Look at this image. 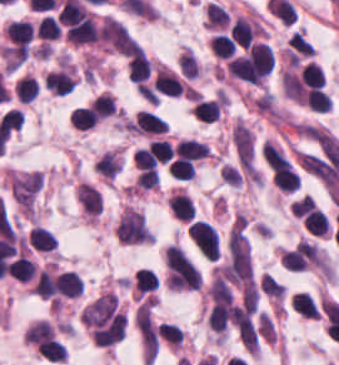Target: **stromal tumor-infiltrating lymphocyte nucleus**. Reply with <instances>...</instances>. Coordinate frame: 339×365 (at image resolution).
Masks as SVG:
<instances>
[{
    "mask_svg": "<svg viewBox=\"0 0 339 365\" xmlns=\"http://www.w3.org/2000/svg\"><path fill=\"white\" fill-rule=\"evenodd\" d=\"M188 236L207 259H218V232L206 221L193 220L188 225Z\"/></svg>",
    "mask_w": 339,
    "mask_h": 365,
    "instance_id": "1",
    "label": "stromal tumor-infiltrating lymphocyte nucleus"
},
{
    "mask_svg": "<svg viewBox=\"0 0 339 365\" xmlns=\"http://www.w3.org/2000/svg\"><path fill=\"white\" fill-rule=\"evenodd\" d=\"M167 124L157 114L147 109H139L129 123V130L146 134H158L164 132Z\"/></svg>",
    "mask_w": 339,
    "mask_h": 365,
    "instance_id": "2",
    "label": "stromal tumor-infiltrating lymphocyte nucleus"
},
{
    "mask_svg": "<svg viewBox=\"0 0 339 365\" xmlns=\"http://www.w3.org/2000/svg\"><path fill=\"white\" fill-rule=\"evenodd\" d=\"M153 86L158 93L177 97L183 88L177 74L162 65L157 68Z\"/></svg>",
    "mask_w": 339,
    "mask_h": 365,
    "instance_id": "3",
    "label": "stromal tumor-infiltrating lymphocyte nucleus"
},
{
    "mask_svg": "<svg viewBox=\"0 0 339 365\" xmlns=\"http://www.w3.org/2000/svg\"><path fill=\"white\" fill-rule=\"evenodd\" d=\"M230 34L236 44L246 49L258 34V23L237 17L232 23Z\"/></svg>",
    "mask_w": 339,
    "mask_h": 365,
    "instance_id": "4",
    "label": "stromal tumor-infiltrating lymphocyte nucleus"
},
{
    "mask_svg": "<svg viewBox=\"0 0 339 365\" xmlns=\"http://www.w3.org/2000/svg\"><path fill=\"white\" fill-rule=\"evenodd\" d=\"M43 85L45 89L63 97L73 90L75 83L72 75L61 69L48 72L45 75Z\"/></svg>",
    "mask_w": 339,
    "mask_h": 365,
    "instance_id": "5",
    "label": "stromal tumor-infiltrating lymphocyte nucleus"
},
{
    "mask_svg": "<svg viewBox=\"0 0 339 365\" xmlns=\"http://www.w3.org/2000/svg\"><path fill=\"white\" fill-rule=\"evenodd\" d=\"M175 153L178 157L198 160L207 157L209 146L197 138H183L176 144Z\"/></svg>",
    "mask_w": 339,
    "mask_h": 365,
    "instance_id": "6",
    "label": "stromal tumor-infiltrating lymphocyte nucleus"
},
{
    "mask_svg": "<svg viewBox=\"0 0 339 365\" xmlns=\"http://www.w3.org/2000/svg\"><path fill=\"white\" fill-rule=\"evenodd\" d=\"M57 293L64 297H78L83 293V284L77 273L62 272L56 280Z\"/></svg>",
    "mask_w": 339,
    "mask_h": 365,
    "instance_id": "7",
    "label": "stromal tumor-infiltrating lymphocyte nucleus"
},
{
    "mask_svg": "<svg viewBox=\"0 0 339 365\" xmlns=\"http://www.w3.org/2000/svg\"><path fill=\"white\" fill-rule=\"evenodd\" d=\"M128 78L138 83H144L150 75V62L138 49L133 53L127 63Z\"/></svg>",
    "mask_w": 339,
    "mask_h": 365,
    "instance_id": "8",
    "label": "stromal tumor-infiltrating lymphocyte nucleus"
},
{
    "mask_svg": "<svg viewBox=\"0 0 339 365\" xmlns=\"http://www.w3.org/2000/svg\"><path fill=\"white\" fill-rule=\"evenodd\" d=\"M293 311L301 317L320 319V310L311 296L305 292L293 293L291 296Z\"/></svg>",
    "mask_w": 339,
    "mask_h": 365,
    "instance_id": "9",
    "label": "stromal tumor-infiltrating lymphocyte nucleus"
},
{
    "mask_svg": "<svg viewBox=\"0 0 339 365\" xmlns=\"http://www.w3.org/2000/svg\"><path fill=\"white\" fill-rule=\"evenodd\" d=\"M28 239L32 247L40 252H52L58 247V241L45 227L34 226Z\"/></svg>",
    "mask_w": 339,
    "mask_h": 365,
    "instance_id": "10",
    "label": "stromal tumor-infiltrating lymphocyte nucleus"
},
{
    "mask_svg": "<svg viewBox=\"0 0 339 365\" xmlns=\"http://www.w3.org/2000/svg\"><path fill=\"white\" fill-rule=\"evenodd\" d=\"M291 60H300L315 54V49L303 33L294 31L287 43Z\"/></svg>",
    "mask_w": 339,
    "mask_h": 365,
    "instance_id": "11",
    "label": "stromal tumor-infiltrating lymphocyte nucleus"
},
{
    "mask_svg": "<svg viewBox=\"0 0 339 365\" xmlns=\"http://www.w3.org/2000/svg\"><path fill=\"white\" fill-rule=\"evenodd\" d=\"M173 217L182 222H191L194 214L193 201L183 192H176L171 198Z\"/></svg>",
    "mask_w": 339,
    "mask_h": 365,
    "instance_id": "12",
    "label": "stromal tumor-infiltrating lymphocyte nucleus"
},
{
    "mask_svg": "<svg viewBox=\"0 0 339 365\" xmlns=\"http://www.w3.org/2000/svg\"><path fill=\"white\" fill-rule=\"evenodd\" d=\"M221 109V99L200 98L193 109V114L200 120L212 122L219 117Z\"/></svg>",
    "mask_w": 339,
    "mask_h": 365,
    "instance_id": "13",
    "label": "stromal tumor-infiltrating lymphocyte nucleus"
},
{
    "mask_svg": "<svg viewBox=\"0 0 339 365\" xmlns=\"http://www.w3.org/2000/svg\"><path fill=\"white\" fill-rule=\"evenodd\" d=\"M7 36L14 44H28L34 29L28 20H14L5 29Z\"/></svg>",
    "mask_w": 339,
    "mask_h": 365,
    "instance_id": "14",
    "label": "stromal tumor-infiltrating lymphocyte nucleus"
},
{
    "mask_svg": "<svg viewBox=\"0 0 339 365\" xmlns=\"http://www.w3.org/2000/svg\"><path fill=\"white\" fill-rule=\"evenodd\" d=\"M210 46L217 58H231L236 53V45L227 34H213Z\"/></svg>",
    "mask_w": 339,
    "mask_h": 365,
    "instance_id": "15",
    "label": "stromal tumor-infiltrating lymphocyte nucleus"
},
{
    "mask_svg": "<svg viewBox=\"0 0 339 365\" xmlns=\"http://www.w3.org/2000/svg\"><path fill=\"white\" fill-rule=\"evenodd\" d=\"M136 291L139 295H144L158 288L157 275L148 267H141L134 273Z\"/></svg>",
    "mask_w": 339,
    "mask_h": 365,
    "instance_id": "16",
    "label": "stromal tumor-infiltrating lymphocyte nucleus"
},
{
    "mask_svg": "<svg viewBox=\"0 0 339 365\" xmlns=\"http://www.w3.org/2000/svg\"><path fill=\"white\" fill-rule=\"evenodd\" d=\"M35 34L38 38L55 39L62 34V27L50 15H43L35 25Z\"/></svg>",
    "mask_w": 339,
    "mask_h": 365,
    "instance_id": "17",
    "label": "stromal tumor-infiltrating lymphocyte nucleus"
},
{
    "mask_svg": "<svg viewBox=\"0 0 339 365\" xmlns=\"http://www.w3.org/2000/svg\"><path fill=\"white\" fill-rule=\"evenodd\" d=\"M38 80L25 75L15 83V94L22 103H30L36 98Z\"/></svg>",
    "mask_w": 339,
    "mask_h": 365,
    "instance_id": "18",
    "label": "stromal tumor-infiltrating lymphocyte nucleus"
},
{
    "mask_svg": "<svg viewBox=\"0 0 339 365\" xmlns=\"http://www.w3.org/2000/svg\"><path fill=\"white\" fill-rule=\"evenodd\" d=\"M167 168L169 175L178 179H192L196 172L192 159L184 157L172 159Z\"/></svg>",
    "mask_w": 339,
    "mask_h": 365,
    "instance_id": "19",
    "label": "stromal tumor-infiltrating lymphocyte nucleus"
},
{
    "mask_svg": "<svg viewBox=\"0 0 339 365\" xmlns=\"http://www.w3.org/2000/svg\"><path fill=\"white\" fill-rule=\"evenodd\" d=\"M229 14L214 3L206 5V25L211 29H221L227 26Z\"/></svg>",
    "mask_w": 339,
    "mask_h": 365,
    "instance_id": "20",
    "label": "stromal tumor-infiltrating lymphocyte nucleus"
},
{
    "mask_svg": "<svg viewBox=\"0 0 339 365\" xmlns=\"http://www.w3.org/2000/svg\"><path fill=\"white\" fill-rule=\"evenodd\" d=\"M69 120L79 129H90L98 122L89 107L78 106L70 114Z\"/></svg>",
    "mask_w": 339,
    "mask_h": 365,
    "instance_id": "21",
    "label": "stromal tumor-infiltrating lymphocyte nucleus"
},
{
    "mask_svg": "<svg viewBox=\"0 0 339 365\" xmlns=\"http://www.w3.org/2000/svg\"><path fill=\"white\" fill-rule=\"evenodd\" d=\"M35 265L29 257L18 255L12 260V276L21 281L33 278Z\"/></svg>",
    "mask_w": 339,
    "mask_h": 365,
    "instance_id": "22",
    "label": "stromal tumor-infiltrating lymphocyte nucleus"
},
{
    "mask_svg": "<svg viewBox=\"0 0 339 365\" xmlns=\"http://www.w3.org/2000/svg\"><path fill=\"white\" fill-rule=\"evenodd\" d=\"M33 293L40 298H49L54 296V282L52 276L45 269H41L38 273L33 285Z\"/></svg>",
    "mask_w": 339,
    "mask_h": 365,
    "instance_id": "23",
    "label": "stromal tumor-infiltrating lymphocyte nucleus"
},
{
    "mask_svg": "<svg viewBox=\"0 0 339 365\" xmlns=\"http://www.w3.org/2000/svg\"><path fill=\"white\" fill-rule=\"evenodd\" d=\"M331 98L325 90L312 89L307 93V107L315 112H328Z\"/></svg>",
    "mask_w": 339,
    "mask_h": 365,
    "instance_id": "24",
    "label": "stromal tumor-infiltrating lymphocyte nucleus"
},
{
    "mask_svg": "<svg viewBox=\"0 0 339 365\" xmlns=\"http://www.w3.org/2000/svg\"><path fill=\"white\" fill-rule=\"evenodd\" d=\"M89 109L100 119L112 115L115 110V106L113 99L106 92L97 96L91 102Z\"/></svg>",
    "mask_w": 339,
    "mask_h": 365,
    "instance_id": "25",
    "label": "stromal tumor-infiltrating lymphocyte nucleus"
},
{
    "mask_svg": "<svg viewBox=\"0 0 339 365\" xmlns=\"http://www.w3.org/2000/svg\"><path fill=\"white\" fill-rule=\"evenodd\" d=\"M178 65L186 78L198 75L199 66L192 50L185 49L178 57Z\"/></svg>",
    "mask_w": 339,
    "mask_h": 365,
    "instance_id": "26",
    "label": "stromal tumor-infiltrating lymphocyte nucleus"
},
{
    "mask_svg": "<svg viewBox=\"0 0 339 365\" xmlns=\"http://www.w3.org/2000/svg\"><path fill=\"white\" fill-rule=\"evenodd\" d=\"M260 284L265 293L278 301L284 293L283 286L267 272L260 278Z\"/></svg>",
    "mask_w": 339,
    "mask_h": 365,
    "instance_id": "27",
    "label": "stromal tumor-infiltrating lymphocyte nucleus"
}]
</instances>
